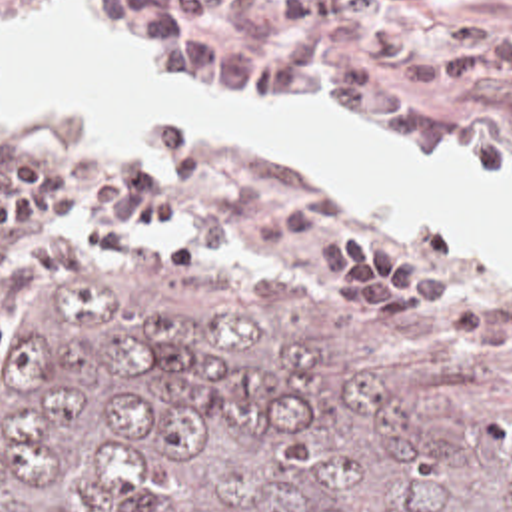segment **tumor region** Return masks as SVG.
<instances>
[{
	"label": "tumor region",
	"mask_w": 512,
	"mask_h": 512,
	"mask_svg": "<svg viewBox=\"0 0 512 512\" xmlns=\"http://www.w3.org/2000/svg\"><path fill=\"white\" fill-rule=\"evenodd\" d=\"M0 512H512V380L157 260L0 308Z\"/></svg>",
	"instance_id": "tumor-region-1"
}]
</instances>
